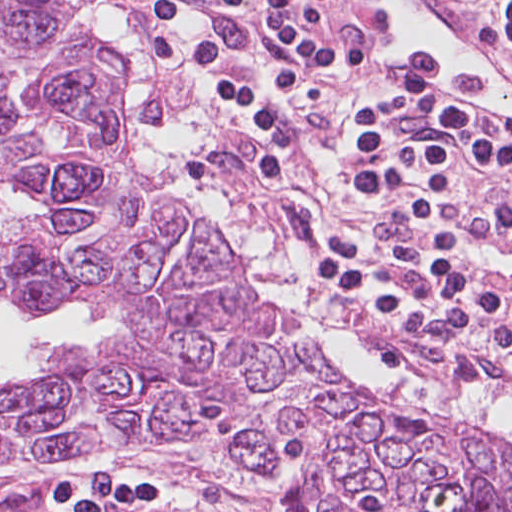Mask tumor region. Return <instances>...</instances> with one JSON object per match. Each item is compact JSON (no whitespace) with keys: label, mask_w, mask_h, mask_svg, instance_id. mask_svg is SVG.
<instances>
[{"label":"tumor region","mask_w":512,"mask_h":512,"mask_svg":"<svg viewBox=\"0 0 512 512\" xmlns=\"http://www.w3.org/2000/svg\"><path fill=\"white\" fill-rule=\"evenodd\" d=\"M95 2L0 0V300L30 320L82 303L137 337L68 346L0 394V461L194 448L284 478L280 512H512L509 443L348 385L138 169L117 107L129 65Z\"/></svg>","instance_id":"e687c5a6"}]
</instances>
